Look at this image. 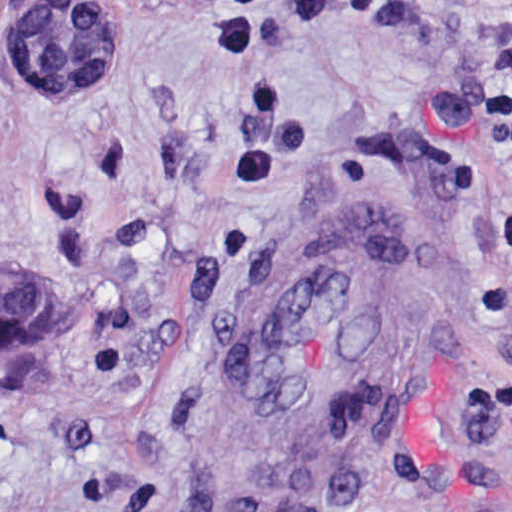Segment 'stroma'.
Returning a JSON list of instances; mask_svg holds the SVG:
<instances>
[{"label":"stroma","mask_w":512,"mask_h":512,"mask_svg":"<svg viewBox=\"0 0 512 512\" xmlns=\"http://www.w3.org/2000/svg\"><path fill=\"white\" fill-rule=\"evenodd\" d=\"M96 1L126 65L29 99L32 0H0V278L57 316L0 357V512H203L223 338L313 218L386 205L423 332L308 512H512V0Z\"/></svg>","instance_id":"35a3bbf8"}]
</instances>
